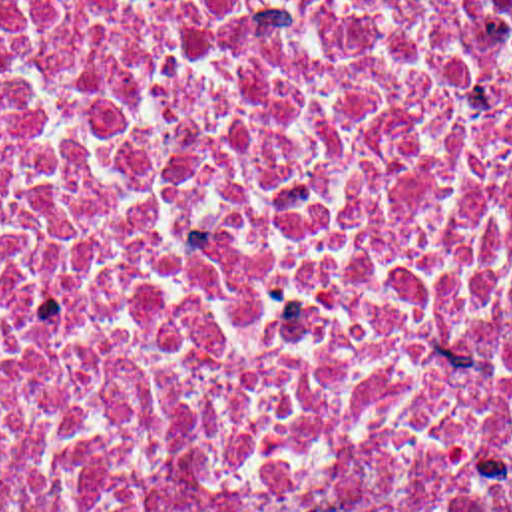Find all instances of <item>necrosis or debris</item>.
I'll list each match as a JSON object with an SVG mask.
<instances>
[{
    "instance_id": "4bbe7bcc",
    "label": "necrosis or debris",
    "mask_w": 512,
    "mask_h": 512,
    "mask_svg": "<svg viewBox=\"0 0 512 512\" xmlns=\"http://www.w3.org/2000/svg\"><path fill=\"white\" fill-rule=\"evenodd\" d=\"M0 512H512V0H0Z\"/></svg>"
}]
</instances>
